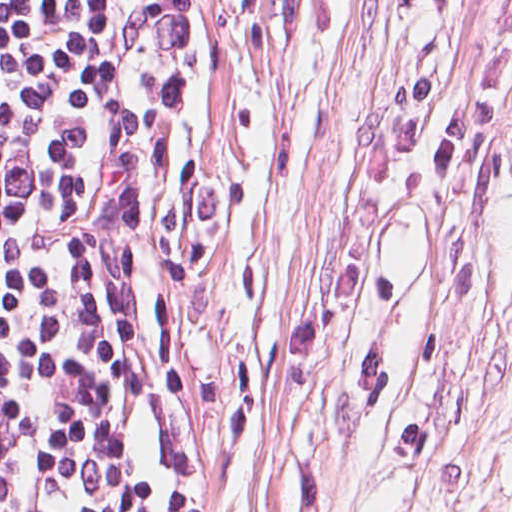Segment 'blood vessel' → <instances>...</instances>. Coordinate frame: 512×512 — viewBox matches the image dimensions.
Masks as SVG:
<instances>
[{
    "mask_svg": "<svg viewBox=\"0 0 512 512\" xmlns=\"http://www.w3.org/2000/svg\"><path fill=\"white\" fill-rule=\"evenodd\" d=\"M504 142L506 146L507 161L512 171V105L504 127Z\"/></svg>",
    "mask_w": 512,
    "mask_h": 512,
    "instance_id": "8fb6f2fc",
    "label": "blood vessel"
}]
</instances>
